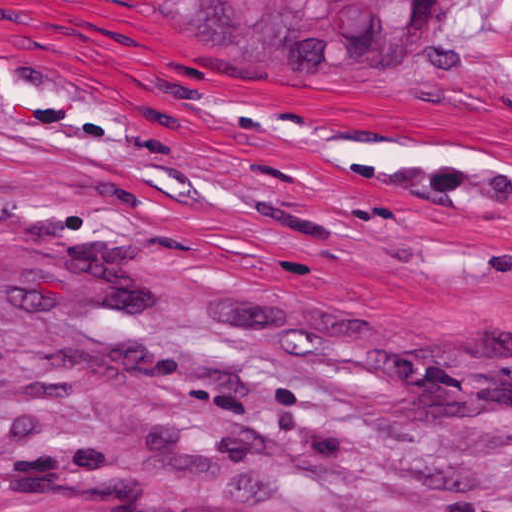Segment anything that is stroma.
<instances>
[{"instance_id": "35a3bbf8", "label": "stroma", "mask_w": 512, "mask_h": 512, "mask_svg": "<svg viewBox=\"0 0 512 512\" xmlns=\"http://www.w3.org/2000/svg\"><path fill=\"white\" fill-rule=\"evenodd\" d=\"M512 512V0L208 51L0 0V490Z\"/></svg>"}]
</instances>
